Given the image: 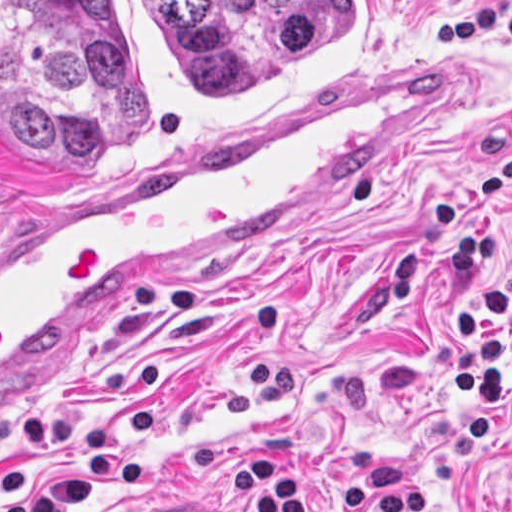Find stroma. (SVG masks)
<instances>
[{
  "label": "stroma",
  "instance_id": "stroma-1",
  "mask_svg": "<svg viewBox=\"0 0 512 512\" xmlns=\"http://www.w3.org/2000/svg\"><path fill=\"white\" fill-rule=\"evenodd\" d=\"M493 67L423 142L315 192L83 337L1 366V239L83 190L201 161L286 129L381 78ZM512 156V0H394L390 43L360 72L243 119L185 153L94 181L1 171L0 512H336L345 453L392 443L417 466L455 421L458 312L475 282L424 251L400 311L388 260L433 199L468 197L512 276V210L485 177ZM512 354L495 417L459 469L423 491L508 512Z\"/></svg>",
  "mask_w": 512,
  "mask_h": 512
}]
</instances>
